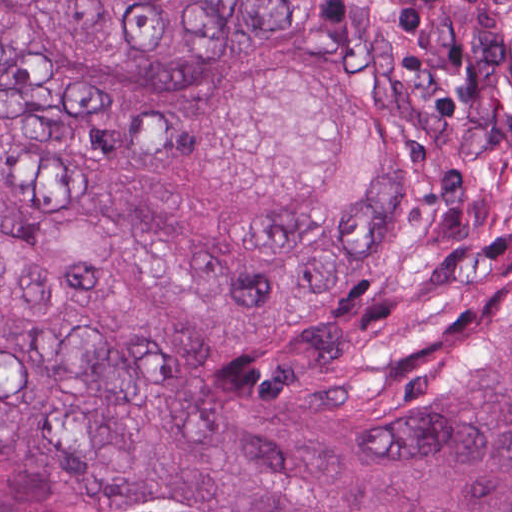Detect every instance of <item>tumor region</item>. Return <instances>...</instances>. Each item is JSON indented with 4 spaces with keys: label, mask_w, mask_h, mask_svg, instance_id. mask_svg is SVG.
<instances>
[{
    "label": "tumor region",
    "mask_w": 512,
    "mask_h": 512,
    "mask_svg": "<svg viewBox=\"0 0 512 512\" xmlns=\"http://www.w3.org/2000/svg\"><path fill=\"white\" fill-rule=\"evenodd\" d=\"M0 512H512V0H0Z\"/></svg>",
    "instance_id": "tumor-region-1"
}]
</instances>
